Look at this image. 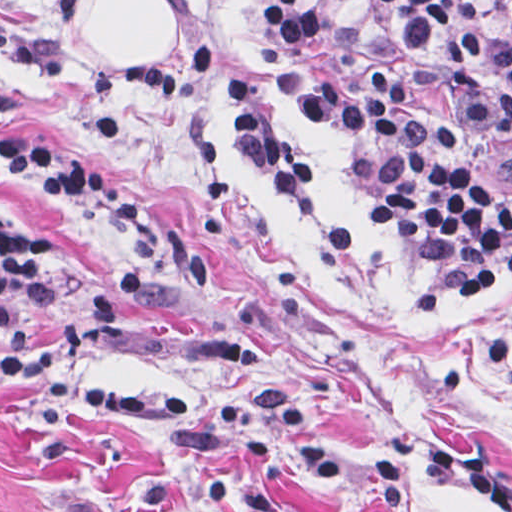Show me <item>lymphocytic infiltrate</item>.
I'll return each instance as SVG.
<instances>
[{"mask_svg": "<svg viewBox=\"0 0 512 512\" xmlns=\"http://www.w3.org/2000/svg\"><path fill=\"white\" fill-rule=\"evenodd\" d=\"M82 0H41L22 33L0 14V56L24 72H59L61 47L49 24L76 22ZM223 4L229 0H214ZM415 50L440 72L446 119L490 145L512 144V0H493L502 22L487 39L460 0H375ZM334 19L321 0H271L254 29L251 60L260 77L303 98L330 129L371 126L410 169L413 182L382 193L370 221L395 229L448 260L444 273L413 290V304L434 309L487 294L512 272V185L467 171L441 143V125L422 103L408 71L378 61L332 64L315 45ZM116 76L171 110L216 99L225 136L243 166L293 198L318 195V173L262 107L252 77L210 44L191 42L187 58L145 53ZM9 173L147 246L156 225L110 177L65 144L0 146ZM92 271L72 266L46 229L0 199V337L34 306L86 286Z\"/></svg>", "mask_w": 512, "mask_h": 512, "instance_id": "1", "label": "lymphocytic infiltrate"}]
</instances>
